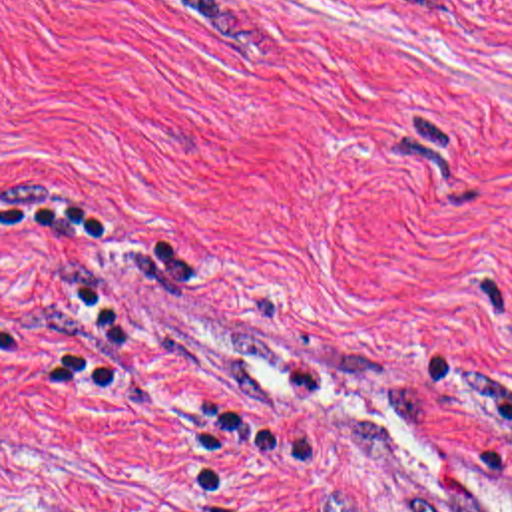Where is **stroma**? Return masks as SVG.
Returning a JSON list of instances; mask_svg holds the SVG:
<instances>
[{"label":"stroma","instance_id":"obj_1","mask_svg":"<svg viewBox=\"0 0 512 512\" xmlns=\"http://www.w3.org/2000/svg\"><path fill=\"white\" fill-rule=\"evenodd\" d=\"M54 194L112 236L2 224ZM62 272L119 391L32 387L92 330ZM510 399L512 0H0V512H512Z\"/></svg>","mask_w":512,"mask_h":512}]
</instances>
